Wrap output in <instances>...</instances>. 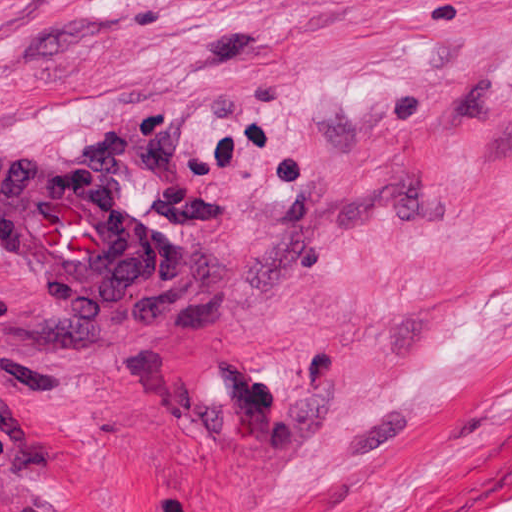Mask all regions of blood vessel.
Masks as SVG:
<instances>
[{
  "instance_id": "1",
  "label": "blood vessel",
  "mask_w": 512,
  "mask_h": 512,
  "mask_svg": "<svg viewBox=\"0 0 512 512\" xmlns=\"http://www.w3.org/2000/svg\"><path fill=\"white\" fill-rule=\"evenodd\" d=\"M0 251L87 314L110 315L131 289L137 224L110 182L0 153Z\"/></svg>"
}]
</instances>
